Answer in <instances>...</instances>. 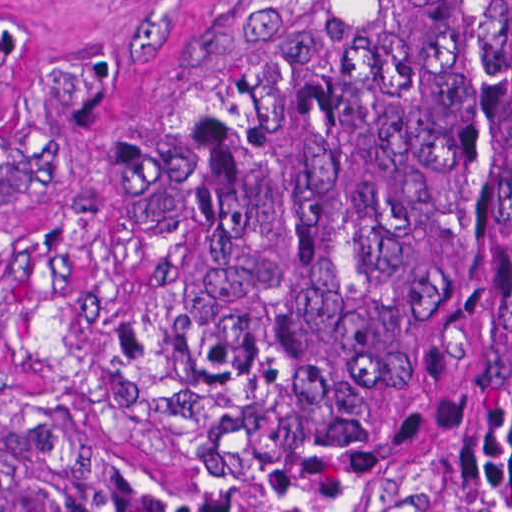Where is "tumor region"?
Returning <instances> with one entry per match:
<instances>
[{"label": "tumor region", "instance_id": "e687c5a6", "mask_svg": "<svg viewBox=\"0 0 512 512\" xmlns=\"http://www.w3.org/2000/svg\"><path fill=\"white\" fill-rule=\"evenodd\" d=\"M18 0H0V64ZM62 85L0 199L84 149ZM218 432L367 512H512V0H281L102 146ZM0 512H184L88 423L0 400Z\"/></svg>", "mask_w": 512, "mask_h": 512}]
</instances>
